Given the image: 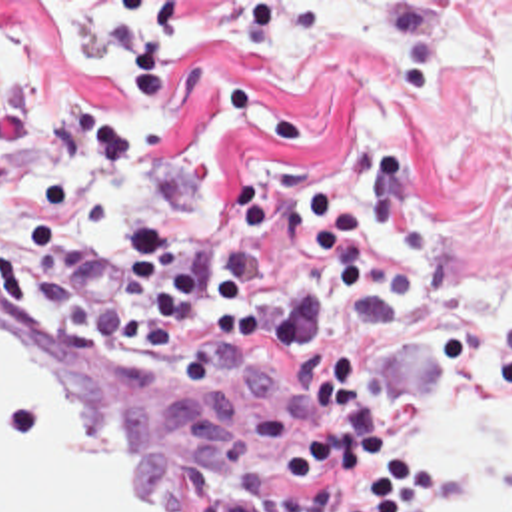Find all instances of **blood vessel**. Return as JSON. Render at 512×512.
I'll list each match as a JSON object with an SVG mask.
<instances>
[{
	"mask_svg": "<svg viewBox=\"0 0 512 512\" xmlns=\"http://www.w3.org/2000/svg\"><path fill=\"white\" fill-rule=\"evenodd\" d=\"M321 409L279 357L93 339L0 284V512H219Z\"/></svg>",
	"mask_w": 512,
	"mask_h": 512,
	"instance_id": "blood-vessel-1",
	"label": "blood vessel"
}]
</instances>
